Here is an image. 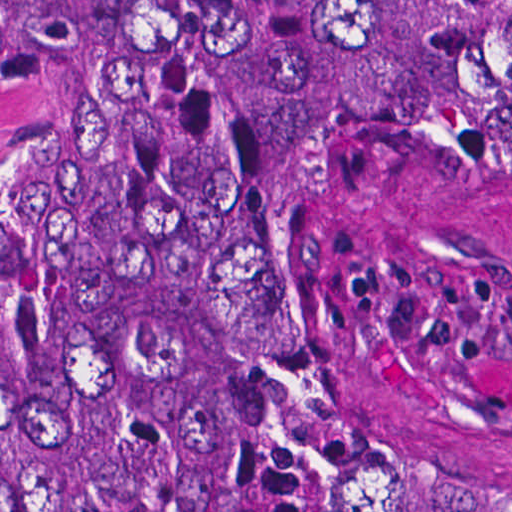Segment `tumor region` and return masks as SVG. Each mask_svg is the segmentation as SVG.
I'll return each mask as SVG.
<instances>
[{"label":"tumor region","mask_w":512,"mask_h":512,"mask_svg":"<svg viewBox=\"0 0 512 512\" xmlns=\"http://www.w3.org/2000/svg\"><path fill=\"white\" fill-rule=\"evenodd\" d=\"M439 146H512V0H0V512H512L318 351Z\"/></svg>","instance_id":"1"}]
</instances>
